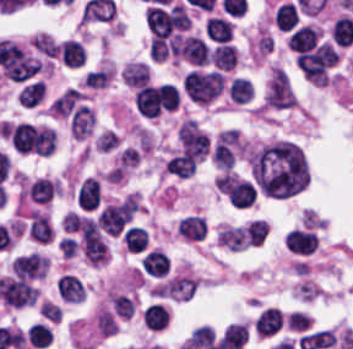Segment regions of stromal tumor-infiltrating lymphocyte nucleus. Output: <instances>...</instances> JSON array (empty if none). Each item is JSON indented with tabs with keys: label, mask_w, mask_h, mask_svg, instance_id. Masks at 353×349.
<instances>
[{
	"label": "stromal tumor-infiltrating lymphocyte nucleus",
	"mask_w": 353,
	"mask_h": 349,
	"mask_svg": "<svg viewBox=\"0 0 353 349\" xmlns=\"http://www.w3.org/2000/svg\"><path fill=\"white\" fill-rule=\"evenodd\" d=\"M298 10L288 0L278 5L275 11V23L281 31H289L297 20Z\"/></svg>",
	"instance_id": "obj_12"
},
{
	"label": "stromal tumor-infiltrating lymphocyte nucleus",
	"mask_w": 353,
	"mask_h": 349,
	"mask_svg": "<svg viewBox=\"0 0 353 349\" xmlns=\"http://www.w3.org/2000/svg\"><path fill=\"white\" fill-rule=\"evenodd\" d=\"M143 320L149 329H162L170 322L167 309L158 303H151L143 312Z\"/></svg>",
	"instance_id": "obj_10"
},
{
	"label": "stromal tumor-infiltrating lymphocyte nucleus",
	"mask_w": 353,
	"mask_h": 349,
	"mask_svg": "<svg viewBox=\"0 0 353 349\" xmlns=\"http://www.w3.org/2000/svg\"><path fill=\"white\" fill-rule=\"evenodd\" d=\"M269 226L266 220H252L246 230V243L261 245L268 234Z\"/></svg>",
	"instance_id": "obj_18"
},
{
	"label": "stromal tumor-infiltrating lymphocyte nucleus",
	"mask_w": 353,
	"mask_h": 349,
	"mask_svg": "<svg viewBox=\"0 0 353 349\" xmlns=\"http://www.w3.org/2000/svg\"><path fill=\"white\" fill-rule=\"evenodd\" d=\"M57 293L68 303H79L86 298L83 279L74 274H61L57 283Z\"/></svg>",
	"instance_id": "obj_3"
},
{
	"label": "stromal tumor-infiltrating lymphocyte nucleus",
	"mask_w": 353,
	"mask_h": 349,
	"mask_svg": "<svg viewBox=\"0 0 353 349\" xmlns=\"http://www.w3.org/2000/svg\"><path fill=\"white\" fill-rule=\"evenodd\" d=\"M230 88L233 102L246 103L253 97L251 80L247 77H234Z\"/></svg>",
	"instance_id": "obj_14"
},
{
	"label": "stromal tumor-infiltrating lymphocyte nucleus",
	"mask_w": 353,
	"mask_h": 349,
	"mask_svg": "<svg viewBox=\"0 0 353 349\" xmlns=\"http://www.w3.org/2000/svg\"><path fill=\"white\" fill-rule=\"evenodd\" d=\"M176 228L180 237L191 242L206 237V219L202 216L190 215L180 219Z\"/></svg>",
	"instance_id": "obj_6"
},
{
	"label": "stromal tumor-infiltrating lymphocyte nucleus",
	"mask_w": 353,
	"mask_h": 349,
	"mask_svg": "<svg viewBox=\"0 0 353 349\" xmlns=\"http://www.w3.org/2000/svg\"><path fill=\"white\" fill-rule=\"evenodd\" d=\"M311 321L308 315L299 309H292L287 313L284 328L291 333H301L310 328Z\"/></svg>",
	"instance_id": "obj_16"
},
{
	"label": "stromal tumor-infiltrating lymphocyte nucleus",
	"mask_w": 353,
	"mask_h": 349,
	"mask_svg": "<svg viewBox=\"0 0 353 349\" xmlns=\"http://www.w3.org/2000/svg\"><path fill=\"white\" fill-rule=\"evenodd\" d=\"M102 199V182L94 176H87L77 186V209Z\"/></svg>",
	"instance_id": "obj_5"
},
{
	"label": "stromal tumor-infiltrating lymphocyte nucleus",
	"mask_w": 353,
	"mask_h": 349,
	"mask_svg": "<svg viewBox=\"0 0 353 349\" xmlns=\"http://www.w3.org/2000/svg\"><path fill=\"white\" fill-rule=\"evenodd\" d=\"M211 60L221 69L233 70L239 61V53L234 44L221 43L213 48Z\"/></svg>",
	"instance_id": "obj_8"
},
{
	"label": "stromal tumor-infiltrating lymphocyte nucleus",
	"mask_w": 353,
	"mask_h": 349,
	"mask_svg": "<svg viewBox=\"0 0 353 349\" xmlns=\"http://www.w3.org/2000/svg\"><path fill=\"white\" fill-rule=\"evenodd\" d=\"M36 125L28 122L14 124L9 136L17 151H30L34 145Z\"/></svg>",
	"instance_id": "obj_4"
},
{
	"label": "stromal tumor-infiltrating lymphocyte nucleus",
	"mask_w": 353,
	"mask_h": 349,
	"mask_svg": "<svg viewBox=\"0 0 353 349\" xmlns=\"http://www.w3.org/2000/svg\"><path fill=\"white\" fill-rule=\"evenodd\" d=\"M56 144V135L53 129H34V151L39 155H50Z\"/></svg>",
	"instance_id": "obj_13"
},
{
	"label": "stromal tumor-infiltrating lymphocyte nucleus",
	"mask_w": 353,
	"mask_h": 349,
	"mask_svg": "<svg viewBox=\"0 0 353 349\" xmlns=\"http://www.w3.org/2000/svg\"><path fill=\"white\" fill-rule=\"evenodd\" d=\"M58 59L63 66L80 68L86 64V46L77 38H63Z\"/></svg>",
	"instance_id": "obj_2"
},
{
	"label": "stromal tumor-infiltrating lymphocyte nucleus",
	"mask_w": 353,
	"mask_h": 349,
	"mask_svg": "<svg viewBox=\"0 0 353 349\" xmlns=\"http://www.w3.org/2000/svg\"><path fill=\"white\" fill-rule=\"evenodd\" d=\"M336 43L350 45L353 42V17L342 15L334 25Z\"/></svg>",
	"instance_id": "obj_15"
},
{
	"label": "stromal tumor-infiltrating lymphocyte nucleus",
	"mask_w": 353,
	"mask_h": 349,
	"mask_svg": "<svg viewBox=\"0 0 353 349\" xmlns=\"http://www.w3.org/2000/svg\"><path fill=\"white\" fill-rule=\"evenodd\" d=\"M285 312L282 308H262L255 318L257 334L266 338L277 336L283 328Z\"/></svg>",
	"instance_id": "obj_1"
},
{
	"label": "stromal tumor-infiltrating lymphocyte nucleus",
	"mask_w": 353,
	"mask_h": 349,
	"mask_svg": "<svg viewBox=\"0 0 353 349\" xmlns=\"http://www.w3.org/2000/svg\"><path fill=\"white\" fill-rule=\"evenodd\" d=\"M28 232L42 242H51L55 236L47 215L34 210L31 211Z\"/></svg>",
	"instance_id": "obj_7"
},
{
	"label": "stromal tumor-infiltrating lymphocyte nucleus",
	"mask_w": 353,
	"mask_h": 349,
	"mask_svg": "<svg viewBox=\"0 0 353 349\" xmlns=\"http://www.w3.org/2000/svg\"><path fill=\"white\" fill-rule=\"evenodd\" d=\"M27 337L31 346L40 349L52 342V334L50 327L47 326L45 323L39 322L34 325H31Z\"/></svg>",
	"instance_id": "obj_17"
},
{
	"label": "stromal tumor-infiltrating lymphocyte nucleus",
	"mask_w": 353,
	"mask_h": 349,
	"mask_svg": "<svg viewBox=\"0 0 353 349\" xmlns=\"http://www.w3.org/2000/svg\"><path fill=\"white\" fill-rule=\"evenodd\" d=\"M206 33L217 42H229L233 35V27L223 16H209L206 22Z\"/></svg>",
	"instance_id": "obj_9"
},
{
	"label": "stromal tumor-infiltrating lymphocyte nucleus",
	"mask_w": 353,
	"mask_h": 349,
	"mask_svg": "<svg viewBox=\"0 0 353 349\" xmlns=\"http://www.w3.org/2000/svg\"><path fill=\"white\" fill-rule=\"evenodd\" d=\"M122 236L127 252H142L147 247L149 236L144 227L133 225Z\"/></svg>",
	"instance_id": "obj_11"
},
{
	"label": "stromal tumor-infiltrating lymphocyte nucleus",
	"mask_w": 353,
	"mask_h": 349,
	"mask_svg": "<svg viewBox=\"0 0 353 349\" xmlns=\"http://www.w3.org/2000/svg\"><path fill=\"white\" fill-rule=\"evenodd\" d=\"M22 104H36L43 97L42 87L37 82H30L25 85L18 94Z\"/></svg>",
	"instance_id": "obj_19"
}]
</instances>
